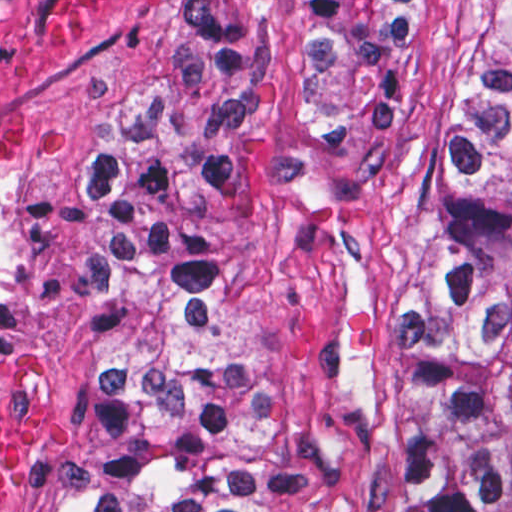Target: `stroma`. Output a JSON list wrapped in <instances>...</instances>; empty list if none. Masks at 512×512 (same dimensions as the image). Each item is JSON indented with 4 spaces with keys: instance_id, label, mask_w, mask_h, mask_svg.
<instances>
[{
    "instance_id": "35a3bbf8",
    "label": "stroma",
    "mask_w": 512,
    "mask_h": 512,
    "mask_svg": "<svg viewBox=\"0 0 512 512\" xmlns=\"http://www.w3.org/2000/svg\"><path fill=\"white\" fill-rule=\"evenodd\" d=\"M188 1H430L427 62L333 179L270 168L223 194L261 380V512H393L375 352L420 241L482 1L0 0V343L39 369L52 424L28 512H62L85 430L100 254L78 167L188 58Z\"/></svg>"
}]
</instances>
